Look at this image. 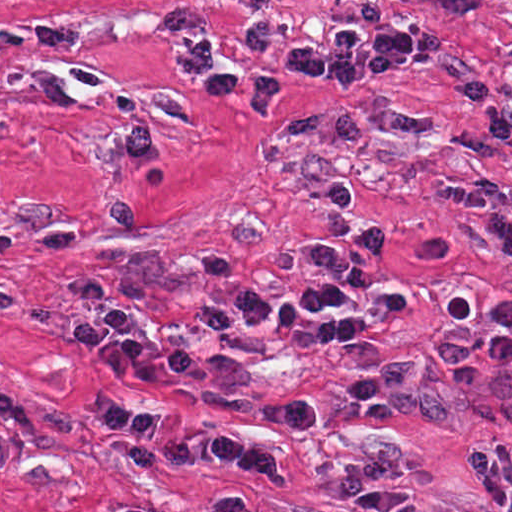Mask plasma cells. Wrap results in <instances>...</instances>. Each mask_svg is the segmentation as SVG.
Masks as SVG:
<instances>
[{
  "mask_svg": "<svg viewBox=\"0 0 512 512\" xmlns=\"http://www.w3.org/2000/svg\"><path fill=\"white\" fill-rule=\"evenodd\" d=\"M440 206L465 217L481 220L492 242L512 267V193L501 188L471 183H447L439 187ZM312 336L320 343H341L365 337V318L359 311L334 302L320 306L311 320ZM431 364L468 401H479L512 373V300L497 310V331L484 337L437 339ZM422 367L416 362L384 361L380 383L361 381L331 392L304 396L278 405H267L255 414L270 425H307L324 421L320 404H346L373 425H384L388 409L404 415H421L440 421L457 420L447 399L428 394L420 386ZM470 476L498 512H512V443H474L465 450Z\"/></svg>",
  "mask_w": 512,
  "mask_h": 512,
  "instance_id": "plasma-cells-1",
  "label": "plasma cells"
}]
</instances>
